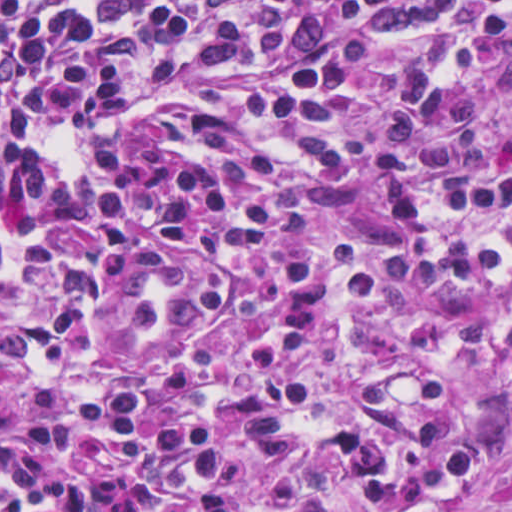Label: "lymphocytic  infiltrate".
Listing matches in <instances>:
<instances>
[{
  "label": "lymphocytic infiltrate",
  "instance_id": "1",
  "mask_svg": "<svg viewBox=\"0 0 512 512\" xmlns=\"http://www.w3.org/2000/svg\"><path fill=\"white\" fill-rule=\"evenodd\" d=\"M512 33V0H0V221L53 207L64 133L127 128L167 95L251 70L237 108L316 176L400 39ZM220 112L196 148L108 140L67 244L0 242V512H463L496 461L456 439L473 383L376 367L351 422L303 426L349 329L392 297L454 312L512 387V91L444 36L391 93L378 154L394 222L376 270L345 238L266 247L272 194L229 169Z\"/></svg>",
  "mask_w": 512,
  "mask_h": 512
}]
</instances>
